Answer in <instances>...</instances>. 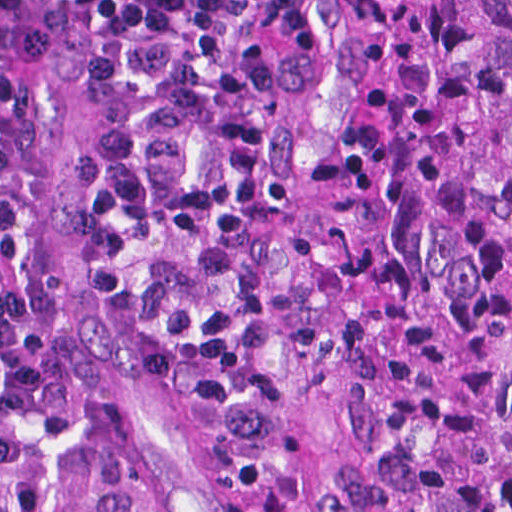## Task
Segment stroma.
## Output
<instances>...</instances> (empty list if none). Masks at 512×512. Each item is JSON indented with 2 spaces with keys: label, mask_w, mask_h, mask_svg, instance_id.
<instances>
[{
  "label": "stroma",
  "mask_w": 512,
  "mask_h": 512,
  "mask_svg": "<svg viewBox=\"0 0 512 512\" xmlns=\"http://www.w3.org/2000/svg\"><path fill=\"white\" fill-rule=\"evenodd\" d=\"M277 172L304 202L298 273L304 292L287 337L309 434L297 455L268 464L216 413L172 405L136 361L101 294L75 159L89 149L93 107L57 95L41 188L43 267L67 307L76 362L124 478L159 512H350L358 476L412 436L387 347L408 312L390 304L353 220L358 198L334 132L343 75L307 0H280Z\"/></svg>",
  "instance_id": "stroma-1"
}]
</instances>
